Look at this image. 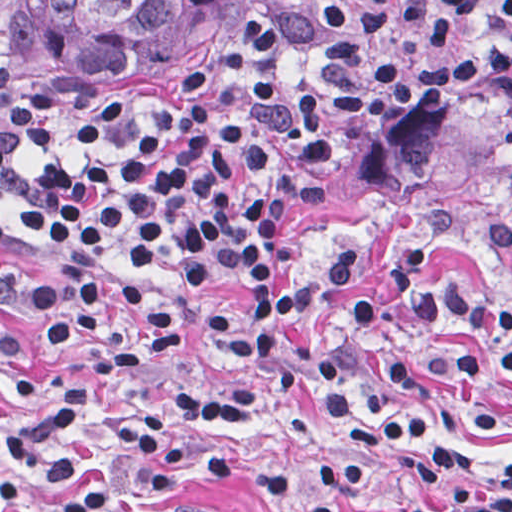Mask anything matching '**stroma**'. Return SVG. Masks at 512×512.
Returning a JSON list of instances; mask_svg holds the SVG:
<instances>
[{
    "instance_id": "stroma-1",
    "label": "stroma",
    "mask_w": 512,
    "mask_h": 512,
    "mask_svg": "<svg viewBox=\"0 0 512 512\" xmlns=\"http://www.w3.org/2000/svg\"><path fill=\"white\" fill-rule=\"evenodd\" d=\"M286 0H250L238 20L211 44L132 85L116 99H86L52 73L17 38L0 44L45 81L68 90L83 106L106 113L143 137L174 145L170 117L189 103L276 15ZM0 141L8 143L21 172L58 160L120 156V146L72 137L33 139L0 109ZM451 207L459 228L433 256L436 285L462 282L471 294L512 300V261L482 236L492 226L512 227V95L494 87L476 94L443 91L413 98L387 129L360 146L334 174L323 203L279 228L277 280L309 275L339 249L361 240V278L346 299L364 294L380 308L376 328L348 359L347 388L362 399L375 371L397 349L439 342L490 341L452 324L423 326L403 309L387 280V265L416 234L423 219ZM0 274L33 285L76 282L111 274L75 265L39 242L0 197ZM247 272H201L182 222L178 175V248L175 261L153 279L181 310L192 333L190 348L165 359L153 374L111 383L100 395L86 433L69 444L86 482L107 478L112 498L105 512H163L180 496L237 512H378L421 492H438L435 480L407 475L445 445L472 442L487 454L512 460V379L492 369L473 383H414L386 405L403 413L420 409L435 422L402 433L364 452L361 481L348 491H325L315 482L335 458V436L320 398L279 394L256 415L211 422L177 412L168 395L216 388L255 373L258 364L219 351L207 312L237 296ZM345 300V301H346ZM298 324L290 343L294 362L307 360L345 302ZM54 370L45 357L40 326L30 330L21 355L0 362V435L25 420L14 386L37 387ZM26 500L0 493V512H50L68 490L30 479Z\"/></svg>"
}]
</instances>
